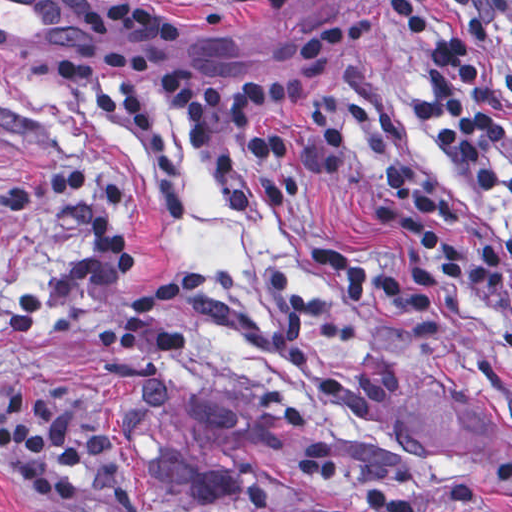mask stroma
<instances>
[{"label": "stroma", "instance_id": "35a3bbf8", "mask_svg": "<svg viewBox=\"0 0 512 512\" xmlns=\"http://www.w3.org/2000/svg\"><path fill=\"white\" fill-rule=\"evenodd\" d=\"M174 58L208 80L267 76L302 30L352 0H310L212 21L186 19ZM461 23L446 0H433ZM70 0H0V189L69 168L92 175L136 248L109 276L61 195L0 213V318L40 293V318L0 343V427L15 388L78 401L94 475L79 494H36L0 450L4 512H371L382 488L415 512H512V308L472 311L369 242L373 169L397 154L490 218L500 207L454 179L408 116L410 66L397 41L349 50L307 128L353 107L364 126L324 183L283 210L222 208L192 132L160 118L180 173L154 178L131 144L58 96L51 64L71 44ZM512 156V108L500 103ZM172 274L205 287L160 315L185 351L105 349L93 322ZM334 447V484L302 477L306 446ZM0 512H2L0 510Z\"/></svg>", "mask_w": 512, "mask_h": 512}]
</instances>
